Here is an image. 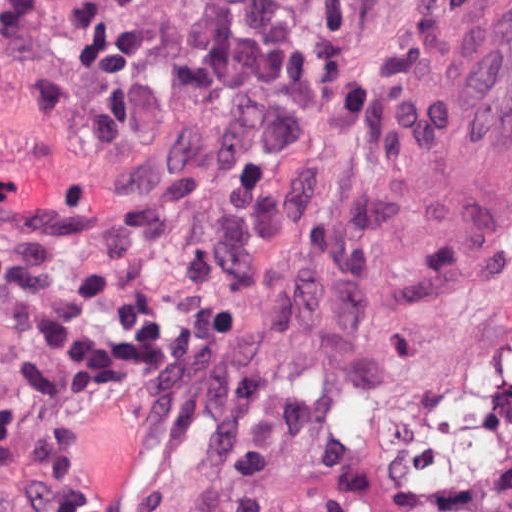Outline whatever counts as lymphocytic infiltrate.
<instances>
[{"label": "lymphocytic infiltrate", "mask_w": 512, "mask_h": 512, "mask_svg": "<svg viewBox=\"0 0 512 512\" xmlns=\"http://www.w3.org/2000/svg\"><path fill=\"white\" fill-rule=\"evenodd\" d=\"M0 433L28 408L73 404L162 329L156 280L65 217L0 213Z\"/></svg>", "instance_id": "f902f5d3"}]
</instances>
